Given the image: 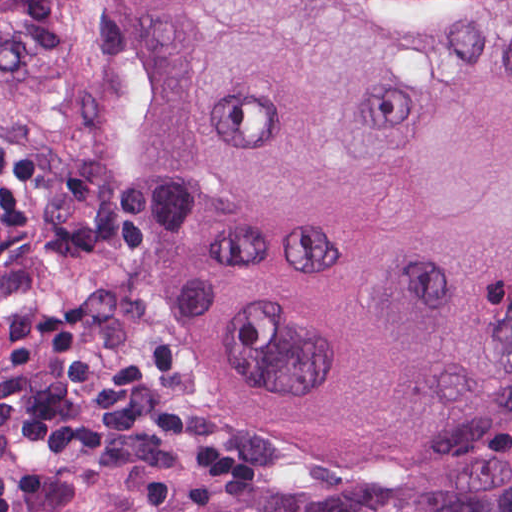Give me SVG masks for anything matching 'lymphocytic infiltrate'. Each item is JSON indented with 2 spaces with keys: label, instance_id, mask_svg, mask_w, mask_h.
Instances as JSON below:
<instances>
[{
  "label": "lymphocytic infiltrate",
  "instance_id": "1",
  "mask_svg": "<svg viewBox=\"0 0 512 512\" xmlns=\"http://www.w3.org/2000/svg\"><path fill=\"white\" fill-rule=\"evenodd\" d=\"M185 378L162 334L114 343L111 302L41 307L0 350V393L15 437L60 466H0V512L55 510L123 473L250 481L251 461L227 437L159 397Z\"/></svg>",
  "mask_w": 512,
  "mask_h": 512
}]
</instances>
